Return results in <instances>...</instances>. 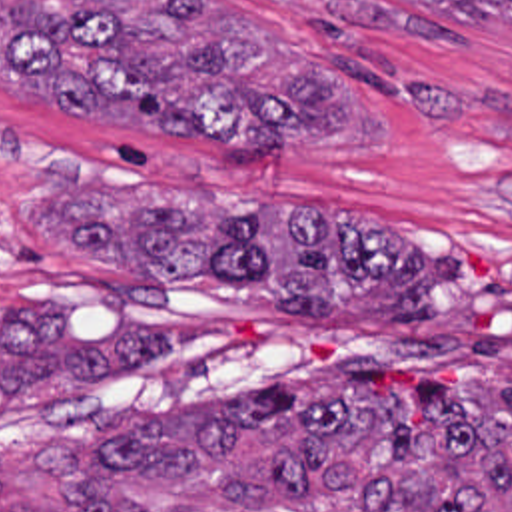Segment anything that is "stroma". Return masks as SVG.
<instances>
[{
	"label": "stroma",
	"instance_id": "1",
	"mask_svg": "<svg viewBox=\"0 0 512 512\" xmlns=\"http://www.w3.org/2000/svg\"><path fill=\"white\" fill-rule=\"evenodd\" d=\"M232 4L308 52L340 86L382 110V142H282L272 168H222L208 138L160 140L148 110L65 116L0 84V340L13 304L49 302L71 340L105 336L123 318L178 326V344L93 382H25L0 421V479L49 481L35 441L69 449L97 483L160 485L111 475L101 437L148 413L252 391L358 360L384 397L416 378H444L462 346L512 338V28L462 22L408 0H212ZM196 190L244 196L296 214L374 220L422 258H442L440 314L426 322H286L244 286L216 278L150 284L41 240L31 210L55 196ZM65 495L115 491L57 483ZM53 497L9 507L29 512Z\"/></svg>",
	"mask_w": 512,
	"mask_h": 512
}]
</instances>
